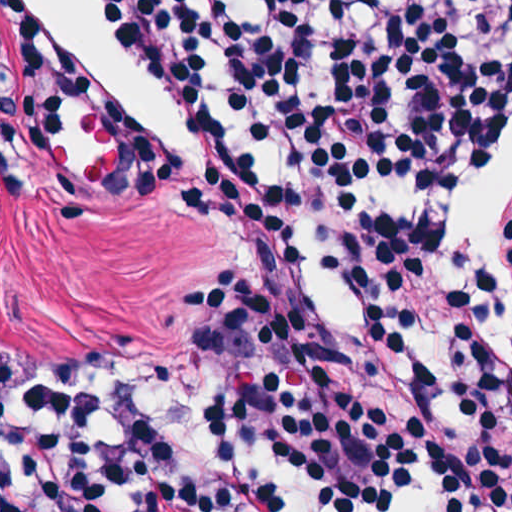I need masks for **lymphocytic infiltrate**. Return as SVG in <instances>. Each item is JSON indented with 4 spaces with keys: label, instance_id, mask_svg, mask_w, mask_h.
<instances>
[{
    "label": "lymphocytic infiltrate",
    "instance_id": "obj_1",
    "mask_svg": "<svg viewBox=\"0 0 512 512\" xmlns=\"http://www.w3.org/2000/svg\"><path fill=\"white\" fill-rule=\"evenodd\" d=\"M202 160L132 140L107 203L162 204L243 237L248 275L185 286L183 322L214 403L129 405L114 347L22 373L1 409V512H102L183 473L148 414H204L254 460L285 457L313 496L378 504L451 485L457 512H512L504 281L448 272L431 225H372L353 307L333 296L336 197L469 182L512 141V0H81ZM18 137L61 116L127 136L116 84L41 0H1ZM217 91V116H216ZM313 320V382H312ZM235 426V427H227ZM139 512H277L259 489L165 492Z\"/></svg>",
    "mask_w": 512,
    "mask_h": 512
}]
</instances>
